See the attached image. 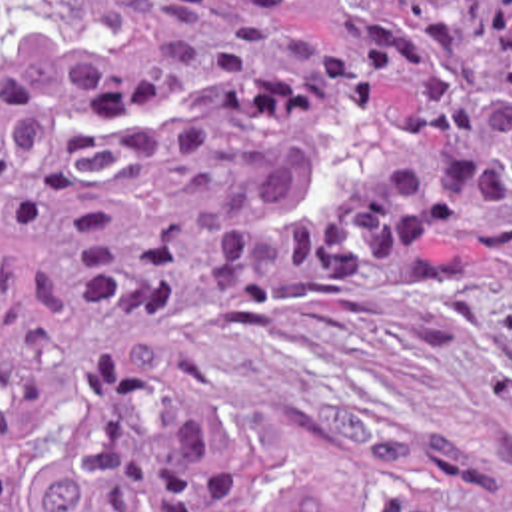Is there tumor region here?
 <instances>
[{"instance_id":"1","label":"tumor region","mask_w":512,"mask_h":512,"mask_svg":"<svg viewBox=\"0 0 512 512\" xmlns=\"http://www.w3.org/2000/svg\"><path fill=\"white\" fill-rule=\"evenodd\" d=\"M307 4L0 0V512H512L269 471L173 332L512 296V0Z\"/></svg>"}]
</instances>
